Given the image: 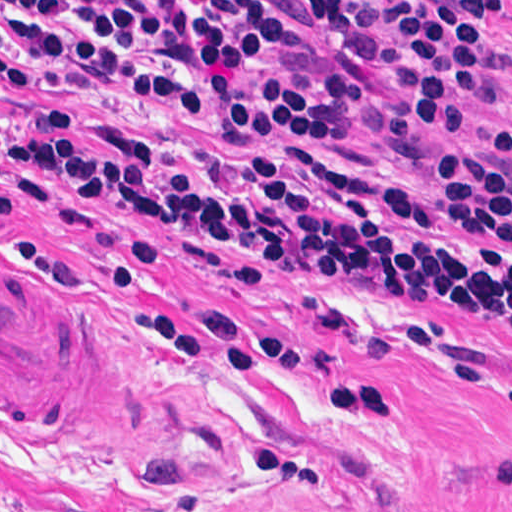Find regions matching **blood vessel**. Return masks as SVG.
<instances>
[{
  "instance_id": "8fb6f2fc",
  "label": "blood vessel",
  "mask_w": 512,
  "mask_h": 512,
  "mask_svg": "<svg viewBox=\"0 0 512 512\" xmlns=\"http://www.w3.org/2000/svg\"><path fill=\"white\" fill-rule=\"evenodd\" d=\"M152 420V387L121 341L0 258V425L122 434Z\"/></svg>"
}]
</instances>
